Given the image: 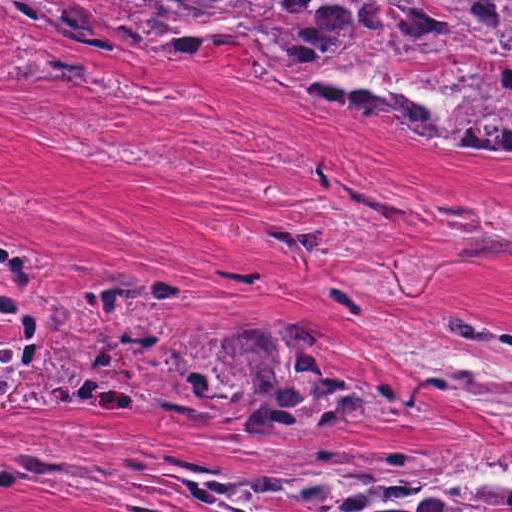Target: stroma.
<instances>
[{
	"instance_id": "1",
	"label": "stroma",
	"mask_w": 512,
	"mask_h": 512,
	"mask_svg": "<svg viewBox=\"0 0 512 512\" xmlns=\"http://www.w3.org/2000/svg\"><path fill=\"white\" fill-rule=\"evenodd\" d=\"M40 252L42 290L113 267L179 287L143 318L192 336L236 382L199 417L0 406L6 512H309L273 488L207 499L174 453L276 474L371 457L491 462L500 445L400 351L466 303L512 318V148L443 152L389 110H336L242 46L186 65L107 58L23 10L0 31V249ZM294 315L327 360L420 412L247 423L231 339Z\"/></svg>"
}]
</instances>
